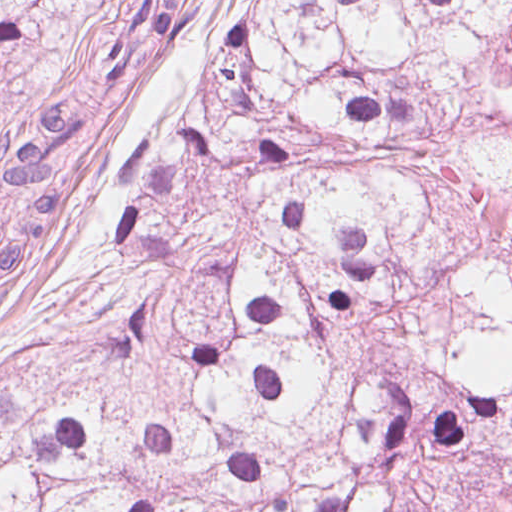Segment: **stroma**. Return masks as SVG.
Returning a JSON list of instances; mask_svg holds the SVG:
<instances>
[{
    "mask_svg": "<svg viewBox=\"0 0 512 512\" xmlns=\"http://www.w3.org/2000/svg\"><path fill=\"white\" fill-rule=\"evenodd\" d=\"M230 0H196L183 43L124 73L100 105L88 172L47 210L22 264L0 287V352L37 335L87 297L112 259L126 215L118 161L164 132L205 80V65L231 19ZM127 25V0H38L0 39V129L33 114L75 54L113 41Z\"/></svg>",
    "mask_w": 512,
    "mask_h": 512,
    "instance_id": "stroma-1",
    "label": "stroma"
}]
</instances>
